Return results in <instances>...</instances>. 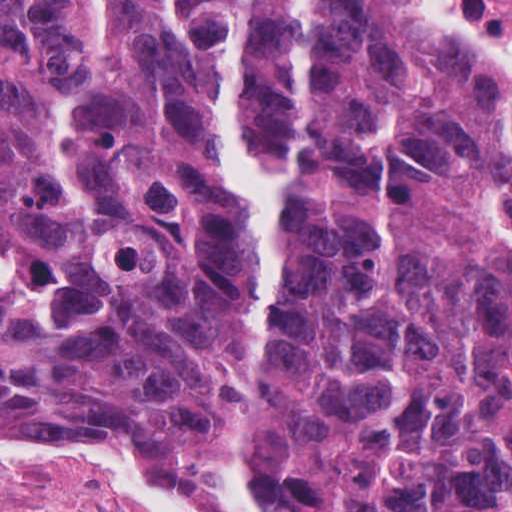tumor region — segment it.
Instances as JSON below:
<instances>
[{"mask_svg": "<svg viewBox=\"0 0 512 512\" xmlns=\"http://www.w3.org/2000/svg\"><path fill=\"white\" fill-rule=\"evenodd\" d=\"M51 415L512 512V97L372 0H0V431Z\"/></svg>", "mask_w": 512, "mask_h": 512, "instance_id": "obj_1", "label": "tumor region"}]
</instances>
